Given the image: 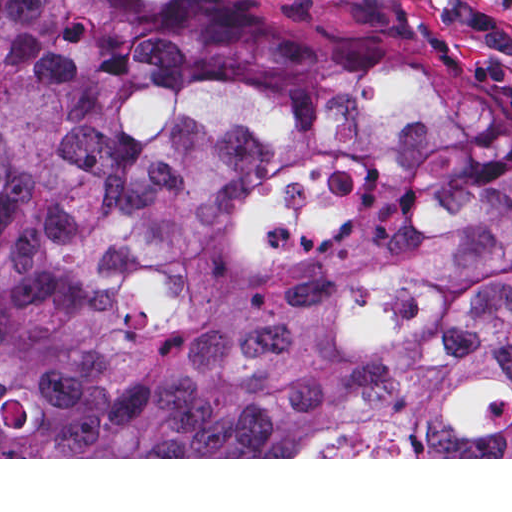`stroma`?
I'll list each match as a JSON object with an SVG mask.
<instances>
[{
    "label": "stroma",
    "instance_id": "obj_1",
    "mask_svg": "<svg viewBox=\"0 0 512 512\" xmlns=\"http://www.w3.org/2000/svg\"><path fill=\"white\" fill-rule=\"evenodd\" d=\"M324 51L411 59L512 116V0H218ZM0 459H512V457H0Z\"/></svg>",
    "mask_w": 512,
    "mask_h": 512
}]
</instances>
